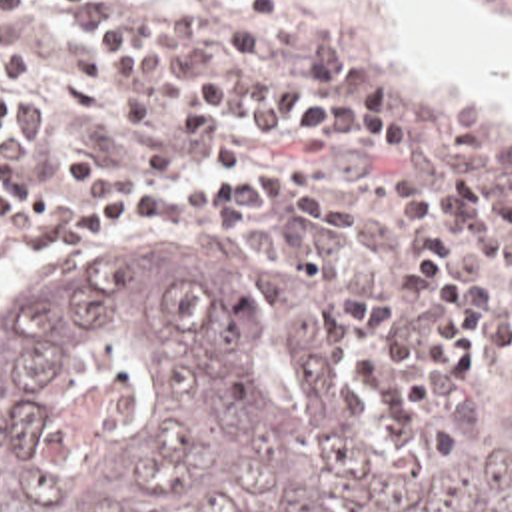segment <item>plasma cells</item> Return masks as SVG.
<instances>
[{
	"label": "plasma cells",
	"mask_w": 512,
	"mask_h": 512,
	"mask_svg": "<svg viewBox=\"0 0 512 512\" xmlns=\"http://www.w3.org/2000/svg\"><path fill=\"white\" fill-rule=\"evenodd\" d=\"M30 5H34V0H0V23L18 17Z\"/></svg>",
	"instance_id": "9512152a"
}]
</instances>
